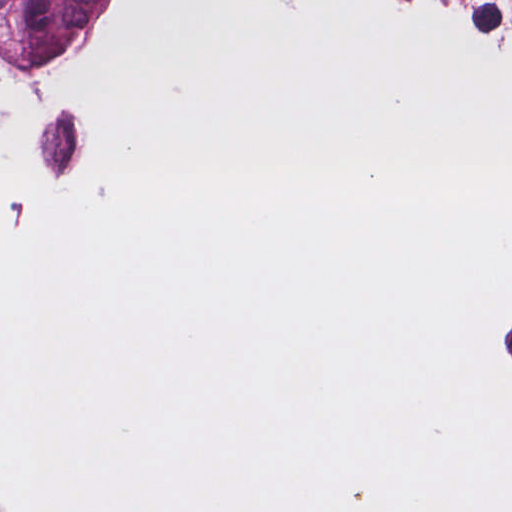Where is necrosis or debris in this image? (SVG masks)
<instances>
[{
  "label": "necrosis or debris",
  "instance_id": "necrosis-or-debris-1",
  "mask_svg": "<svg viewBox=\"0 0 512 512\" xmlns=\"http://www.w3.org/2000/svg\"><path fill=\"white\" fill-rule=\"evenodd\" d=\"M457 363L477 424L512 465V261L487 275L463 306Z\"/></svg>",
  "mask_w": 512,
  "mask_h": 512
}]
</instances>
